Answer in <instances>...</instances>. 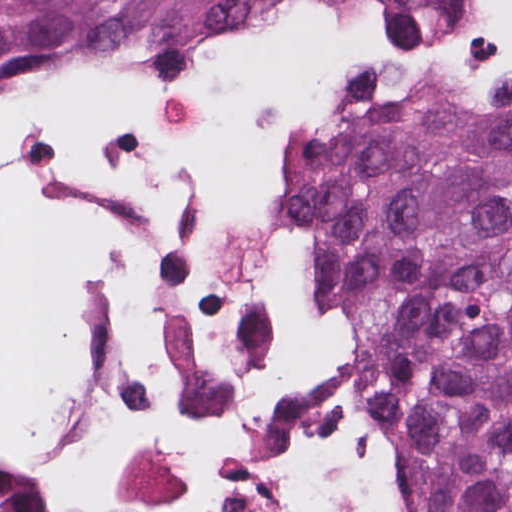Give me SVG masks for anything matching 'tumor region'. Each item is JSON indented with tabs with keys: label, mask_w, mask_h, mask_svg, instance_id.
<instances>
[{
	"label": "tumor region",
	"mask_w": 512,
	"mask_h": 512,
	"mask_svg": "<svg viewBox=\"0 0 512 512\" xmlns=\"http://www.w3.org/2000/svg\"><path fill=\"white\" fill-rule=\"evenodd\" d=\"M255 0H0V54L196 61ZM391 39L484 0H345ZM418 512H512V45L477 93L352 105L290 152Z\"/></svg>",
	"instance_id": "tumor-region-1"
}]
</instances>
